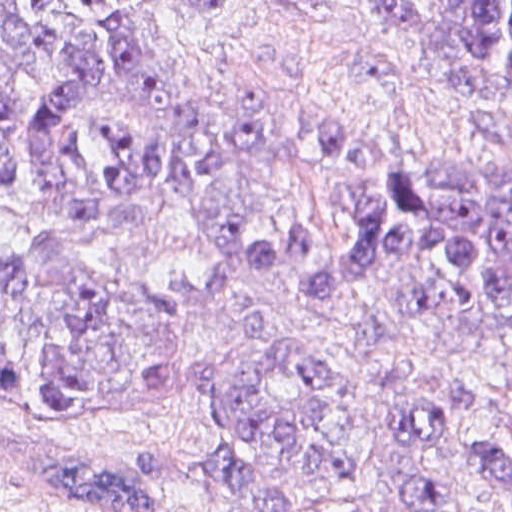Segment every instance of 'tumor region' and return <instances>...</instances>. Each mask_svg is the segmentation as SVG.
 <instances>
[{
    "label": "tumor region",
    "instance_id": "tumor-region-1",
    "mask_svg": "<svg viewBox=\"0 0 512 512\" xmlns=\"http://www.w3.org/2000/svg\"><path fill=\"white\" fill-rule=\"evenodd\" d=\"M229 1L183 8L205 16ZM363 1L409 30L473 113L499 105L512 120V0H443L438 22L412 0ZM376 144L318 125L317 154L340 164L363 163ZM268 174V130L192 91L163 50L152 0H0V193L28 195L63 221L124 225L144 217L141 198L158 187L216 240L205 283L162 288L104 281L55 235L34 249L0 242V376L55 417L181 397L163 392L179 387L184 331L239 275ZM331 204L350 214L346 240L301 219L265 240L258 268L308 269L296 288L314 300L388 269L382 293L338 333L376 354L422 329L495 333L512 396V166L399 155L372 187L342 186ZM245 331L264 343L256 360L200 358L202 465L255 512L351 491L349 431L364 387L324 347L289 346L258 319ZM484 402L477 381L421 391L398 408L394 437L416 455L458 448L512 496V438L463 426ZM38 472L90 512L156 511L144 475L63 437H46Z\"/></svg>",
    "mask_w": 512,
    "mask_h": 512
}]
</instances>
